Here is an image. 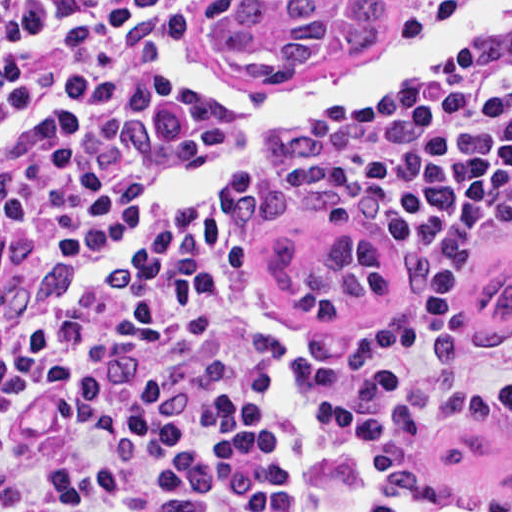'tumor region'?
I'll use <instances>...</instances> for the list:
<instances>
[{"mask_svg":"<svg viewBox=\"0 0 512 512\" xmlns=\"http://www.w3.org/2000/svg\"><path fill=\"white\" fill-rule=\"evenodd\" d=\"M382 0H222L201 43L217 67L247 79H294L380 35ZM364 512H512V417L411 454Z\"/></svg>","mask_w":512,"mask_h":512,"instance_id":"e687c5a6","label":"tumor region"}]
</instances>
